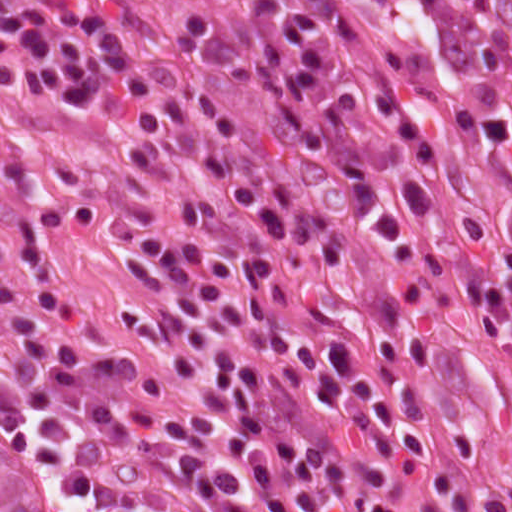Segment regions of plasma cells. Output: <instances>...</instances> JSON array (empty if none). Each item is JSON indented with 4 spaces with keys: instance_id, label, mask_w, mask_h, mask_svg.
<instances>
[{
    "instance_id": "9512152a",
    "label": "plasma cells",
    "mask_w": 512,
    "mask_h": 512,
    "mask_svg": "<svg viewBox=\"0 0 512 512\" xmlns=\"http://www.w3.org/2000/svg\"><path fill=\"white\" fill-rule=\"evenodd\" d=\"M0 0V85L156 140L131 178L55 195L117 263L125 329L78 287L0 278V415L65 512H498L469 413L393 266L425 248L444 144L411 96L372 107L408 153L370 213L290 0ZM469 285L512 334V253ZM503 499L512 510V484Z\"/></svg>"
}]
</instances>
